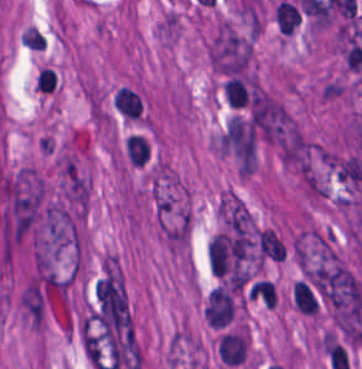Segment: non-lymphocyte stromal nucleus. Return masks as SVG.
Returning a JSON list of instances; mask_svg holds the SVG:
<instances>
[{
	"label": "non-lymphocyte stromal nucleus",
	"instance_id": "1",
	"mask_svg": "<svg viewBox=\"0 0 362 369\" xmlns=\"http://www.w3.org/2000/svg\"><path fill=\"white\" fill-rule=\"evenodd\" d=\"M211 61L226 76L251 75V41L229 26H221L211 45Z\"/></svg>",
	"mask_w": 362,
	"mask_h": 369
},
{
	"label": "non-lymphocyte stromal nucleus",
	"instance_id": "2",
	"mask_svg": "<svg viewBox=\"0 0 362 369\" xmlns=\"http://www.w3.org/2000/svg\"><path fill=\"white\" fill-rule=\"evenodd\" d=\"M301 20L297 5L281 0L276 8L275 21L282 35H291Z\"/></svg>",
	"mask_w": 362,
	"mask_h": 369
}]
</instances>
